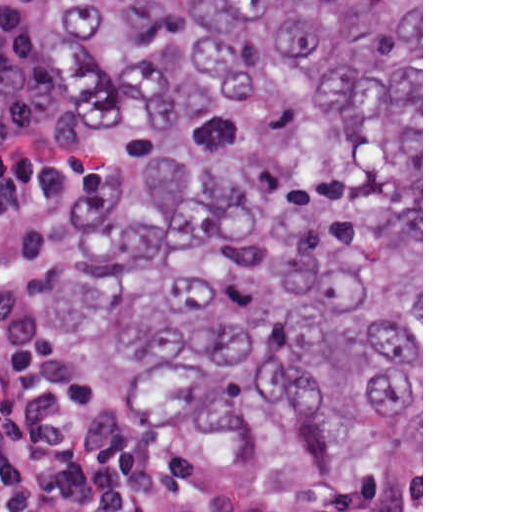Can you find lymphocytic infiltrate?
<instances>
[{
  "mask_svg": "<svg viewBox=\"0 0 512 512\" xmlns=\"http://www.w3.org/2000/svg\"><path fill=\"white\" fill-rule=\"evenodd\" d=\"M87 166L56 100L51 0H0V268L84 214ZM0 512H421L392 488L300 499L282 470L196 448L170 423L29 353L0 327Z\"/></svg>",
  "mask_w": 512,
  "mask_h": 512,
  "instance_id": "1",
  "label": "lymphocytic infiltrate"
}]
</instances>
